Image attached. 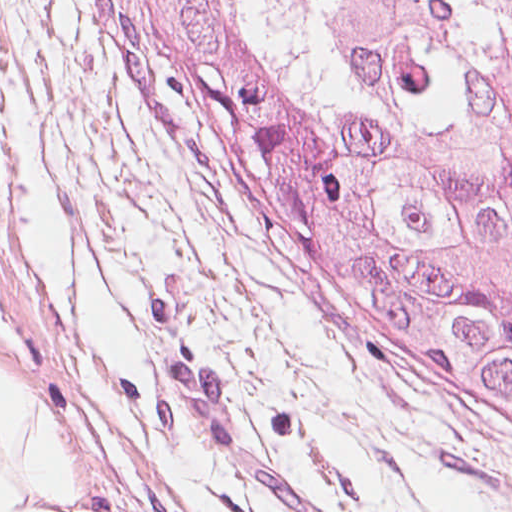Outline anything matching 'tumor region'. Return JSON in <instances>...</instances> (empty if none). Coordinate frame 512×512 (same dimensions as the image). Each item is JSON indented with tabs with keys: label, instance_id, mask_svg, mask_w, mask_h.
Listing matches in <instances>:
<instances>
[{
	"label": "tumor region",
	"instance_id": "obj_1",
	"mask_svg": "<svg viewBox=\"0 0 512 512\" xmlns=\"http://www.w3.org/2000/svg\"><path fill=\"white\" fill-rule=\"evenodd\" d=\"M240 211L512 270V0H96Z\"/></svg>",
	"mask_w": 512,
	"mask_h": 512
}]
</instances>
